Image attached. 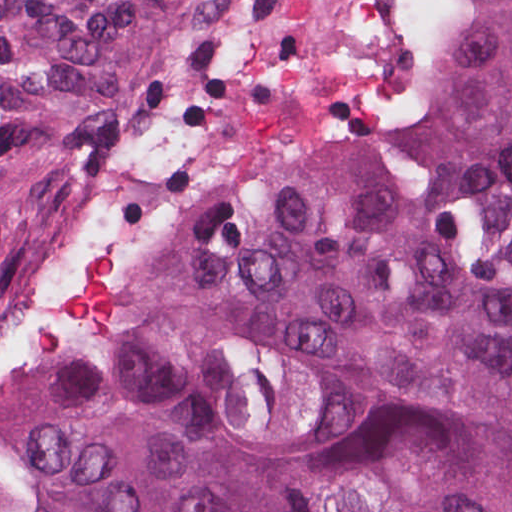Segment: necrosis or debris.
<instances>
[{
  "instance_id": "4bbe7bcc",
  "label": "necrosis or debris",
  "mask_w": 512,
  "mask_h": 512,
  "mask_svg": "<svg viewBox=\"0 0 512 512\" xmlns=\"http://www.w3.org/2000/svg\"><path fill=\"white\" fill-rule=\"evenodd\" d=\"M209 175L193 85L162 75L59 261L0 335V512L78 401L126 359Z\"/></svg>"
}]
</instances>
